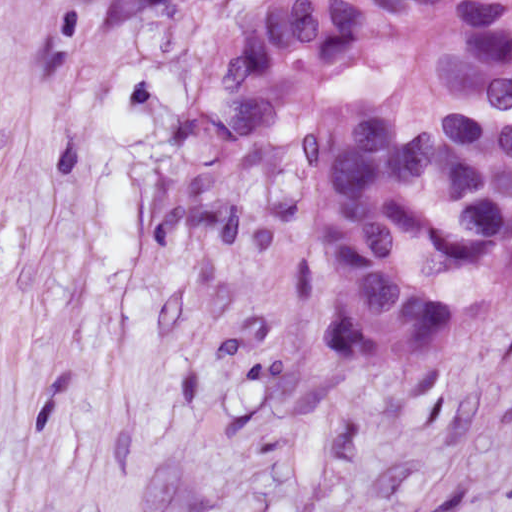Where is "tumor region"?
Returning a JSON list of instances; mask_svg holds the SVG:
<instances>
[{
  "label": "tumor region",
  "instance_id": "e687c5a6",
  "mask_svg": "<svg viewBox=\"0 0 512 512\" xmlns=\"http://www.w3.org/2000/svg\"><path fill=\"white\" fill-rule=\"evenodd\" d=\"M177 1L27 0L32 45L52 65ZM161 216L245 259L310 239L339 374L454 337L512 282V0H295L201 75Z\"/></svg>",
  "mask_w": 512,
  "mask_h": 512
}]
</instances>
